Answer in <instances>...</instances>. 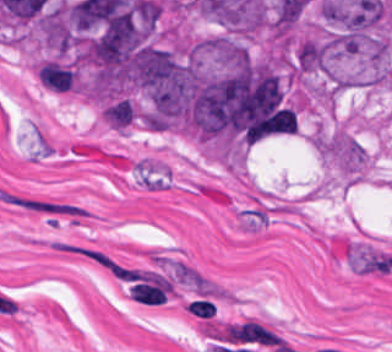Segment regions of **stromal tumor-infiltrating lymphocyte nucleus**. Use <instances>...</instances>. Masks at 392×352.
<instances>
[{
	"label": "stromal tumor-infiltrating lymphocyte nucleus",
	"instance_id": "obj_1",
	"mask_svg": "<svg viewBox=\"0 0 392 352\" xmlns=\"http://www.w3.org/2000/svg\"><path fill=\"white\" fill-rule=\"evenodd\" d=\"M185 304L190 314L206 318L212 315L216 310V308L207 298H194Z\"/></svg>",
	"mask_w": 392,
	"mask_h": 352
}]
</instances>
